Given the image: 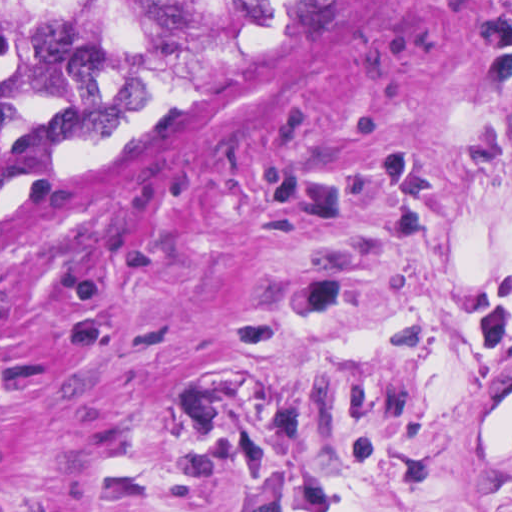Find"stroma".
I'll use <instances>...</instances> for the list:
<instances>
[{"mask_svg":"<svg viewBox=\"0 0 512 512\" xmlns=\"http://www.w3.org/2000/svg\"><path fill=\"white\" fill-rule=\"evenodd\" d=\"M0 512H512V0H338L1 194Z\"/></svg>","mask_w":512,"mask_h":512,"instance_id":"stroma-1","label":"stroma"}]
</instances>
